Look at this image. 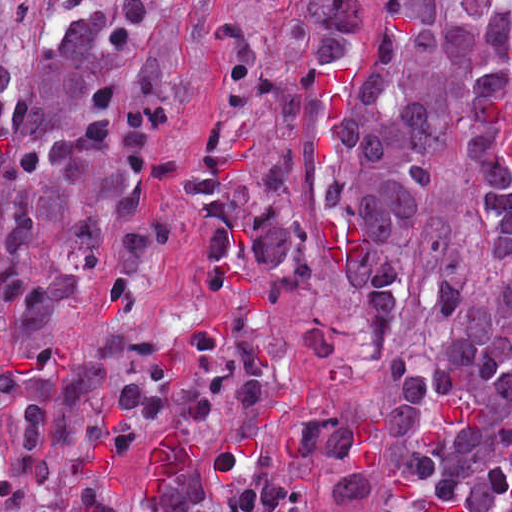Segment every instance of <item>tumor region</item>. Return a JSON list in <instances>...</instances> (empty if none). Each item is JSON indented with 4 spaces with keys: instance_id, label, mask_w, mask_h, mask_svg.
I'll return each instance as SVG.
<instances>
[{
    "instance_id": "1",
    "label": "tumor region",
    "mask_w": 512,
    "mask_h": 512,
    "mask_svg": "<svg viewBox=\"0 0 512 512\" xmlns=\"http://www.w3.org/2000/svg\"><path fill=\"white\" fill-rule=\"evenodd\" d=\"M19 0H0V21ZM382 387L283 410L307 189L277 138L185 164L206 297L51 365L0 368V512H512V0H240L207 46L228 103L331 118ZM184 0H52L19 83L0 34V323L34 354L87 289L128 306L161 257Z\"/></svg>"
}]
</instances>
